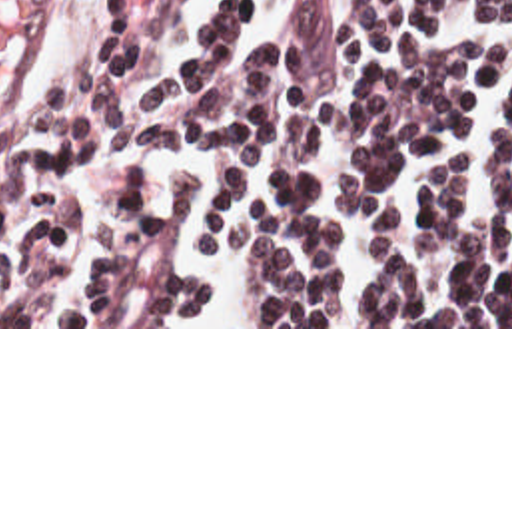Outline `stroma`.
<instances>
[{"label":"stroma","mask_w":512,"mask_h":512,"mask_svg":"<svg viewBox=\"0 0 512 512\" xmlns=\"http://www.w3.org/2000/svg\"><path fill=\"white\" fill-rule=\"evenodd\" d=\"M71 0H0V123L41 77ZM0 329H512V327H0Z\"/></svg>","instance_id":"obj_1"}]
</instances>
